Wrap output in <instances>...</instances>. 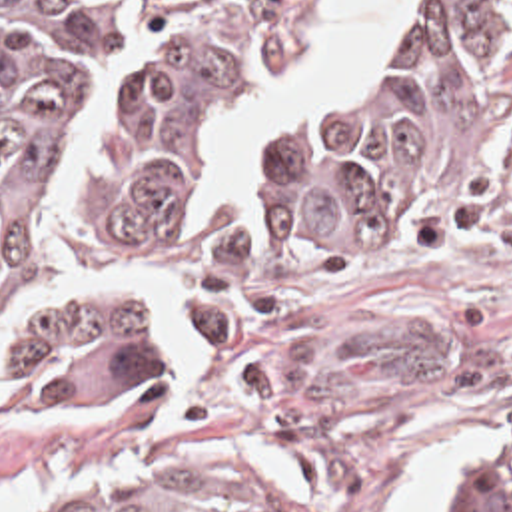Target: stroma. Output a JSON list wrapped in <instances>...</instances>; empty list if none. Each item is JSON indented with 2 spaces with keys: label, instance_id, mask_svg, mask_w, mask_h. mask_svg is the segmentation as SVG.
Returning a JSON list of instances; mask_svg holds the SVG:
<instances>
[{
  "label": "stroma",
  "instance_id": "stroma-1",
  "mask_svg": "<svg viewBox=\"0 0 512 512\" xmlns=\"http://www.w3.org/2000/svg\"><path fill=\"white\" fill-rule=\"evenodd\" d=\"M327 1L305 49L279 63L229 131L190 273L217 233L259 209L273 133L377 71L431 3H409L399 39L265 127L257 175L223 205L243 123L297 81ZM154 329L172 355L166 399L16 407L0 391V482L38 476L10 512L76 476L130 466L227 470L255 480L277 512H401L453 432L493 429L512 458V141L461 213L283 297L247 345L209 349L186 321V299ZM457 476H491L512 512L503 462L439 464L415 512H429L435 486Z\"/></svg>",
  "mask_w": 512,
  "mask_h": 512
}]
</instances>
